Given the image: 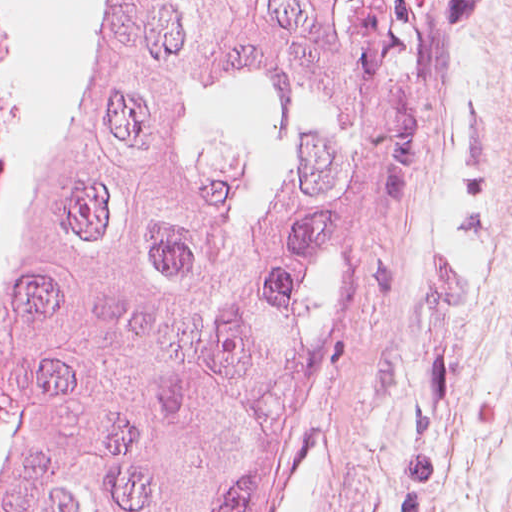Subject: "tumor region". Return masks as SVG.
<instances>
[{"mask_svg": "<svg viewBox=\"0 0 512 512\" xmlns=\"http://www.w3.org/2000/svg\"><path fill=\"white\" fill-rule=\"evenodd\" d=\"M0 512H287L411 57L376 0H4Z\"/></svg>", "mask_w": 512, "mask_h": 512, "instance_id": "1", "label": "tumor region"}]
</instances>
